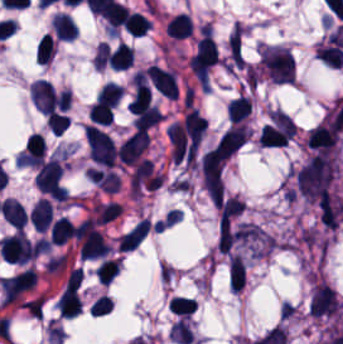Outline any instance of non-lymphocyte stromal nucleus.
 Instances as JSON below:
<instances>
[{
    "label": "non-lymphocyte stromal nucleus",
    "instance_id": "obj_1",
    "mask_svg": "<svg viewBox=\"0 0 343 344\" xmlns=\"http://www.w3.org/2000/svg\"><path fill=\"white\" fill-rule=\"evenodd\" d=\"M226 159L214 147L200 159L201 180L213 200H222Z\"/></svg>",
    "mask_w": 343,
    "mask_h": 344
}]
</instances>
